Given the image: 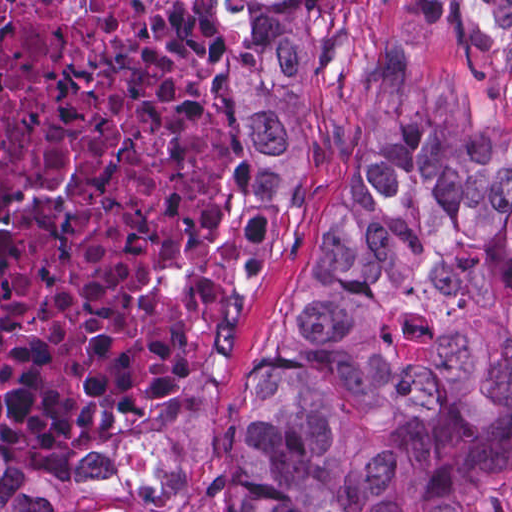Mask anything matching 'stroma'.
Here are the masks:
<instances>
[{
  "mask_svg": "<svg viewBox=\"0 0 512 512\" xmlns=\"http://www.w3.org/2000/svg\"><path fill=\"white\" fill-rule=\"evenodd\" d=\"M229 137L215 224L163 271L174 290L215 275V323L195 363L163 394L121 416L98 452L34 446L0 421V443L33 471L84 490L100 512H210L228 493L242 414L274 320L332 230L340 190L391 93L449 81L512 143V0H328L339 90H315L303 174L288 189L250 174L254 135H230L220 50L206 0H191ZM493 512H512V468ZM411 512H439L434 503Z\"/></svg>",
  "mask_w": 512,
  "mask_h": 512,
  "instance_id": "stroma-1",
  "label": "stroma"
}]
</instances>
